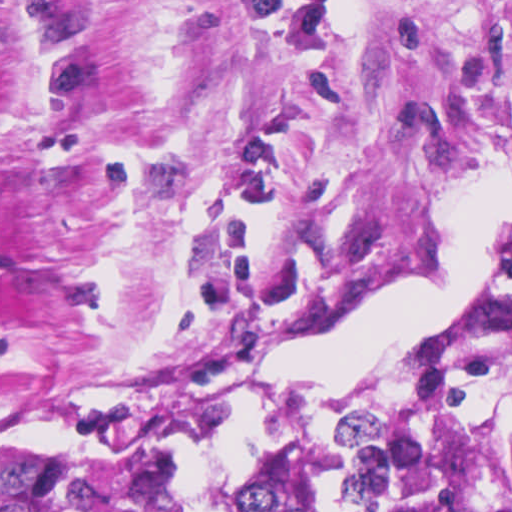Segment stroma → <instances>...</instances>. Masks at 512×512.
Masks as SVG:
<instances>
[{
    "mask_svg": "<svg viewBox=\"0 0 512 512\" xmlns=\"http://www.w3.org/2000/svg\"><path fill=\"white\" fill-rule=\"evenodd\" d=\"M510 128L512 0H0V428L253 388Z\"/></svg>",
    "mask_w": 512,
    "mask_h": 512,
    "instance_id": "obj_1",
    "label": "stroma"
}]
</instances>
